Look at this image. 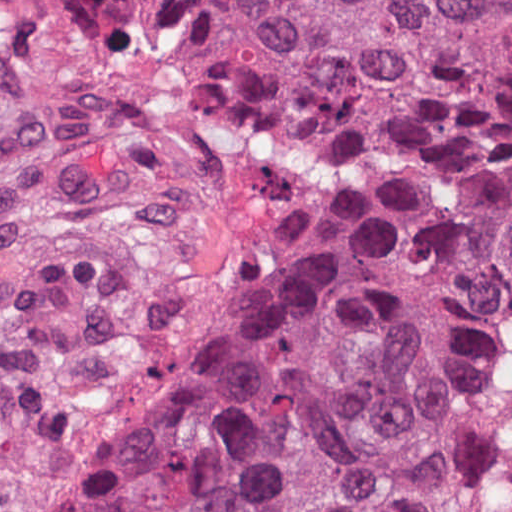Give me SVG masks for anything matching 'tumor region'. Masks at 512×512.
Here are the masks:
<instances>
[{"label":"tumor region","mask_w":512,"mask_h":512,"mask_svg":"<svg viewBox=\"0 0 512 512\" xmlns=\"http://www.w3.org/2000/svg\"><path fill=\"white\" fill-rule=\"evenodd\" d=\"M83 47L218 35L370 146L88 512H512V0H50Z\"/></svg>","instance_id":"obj_1"}]
</instances>
